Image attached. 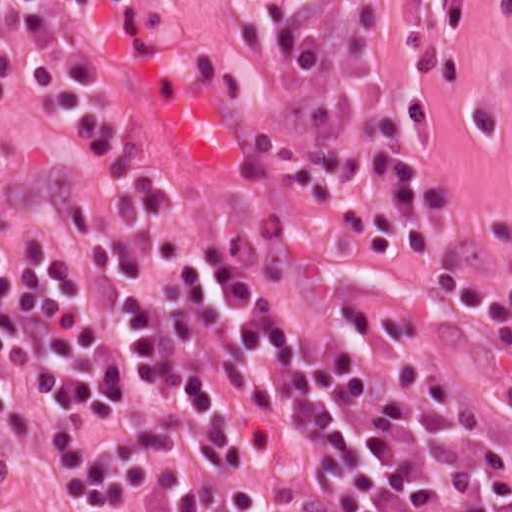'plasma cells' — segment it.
Listing matches in <instances>:
<instances>
[{"label":"plasma cells","mask_w":512,"mask_h":512,"mask_svg":"<svg viewBox=\"0 0 512 512\" xmlns=\"http://www.w3.org/2000/svg\"><path fill=\"white\" fill-rule=\"evenodd\" d=\"M47 0H0L40 19ZM154 10L169 0H87ZM418 0H258L264 119L313 212L356 189L360 248L402 250L437 296L496 324L512 277L458 269L453 203L404 149L399 108ZM70 145L43 158L0 131V438L33 512H512V432L466 413L440 359L272 264L197 240L146 181L105 83L57 77Z\"/></svg>","instance_id":"obj_1"}]
</instances>
